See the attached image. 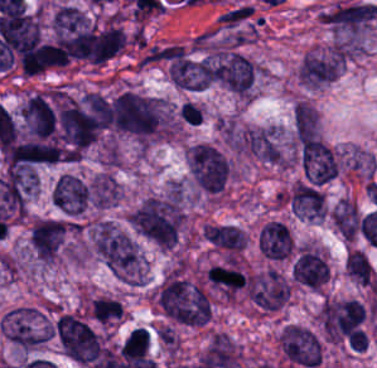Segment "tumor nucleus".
Here are the masks:
<instances>
[{"label": "tumor nucleus", "instance_id": "tumor-nucleus-17", "mask_svg": "<svg viewBox=\"0 0 377 368\" xmlns=\"http://www.w3.org/2000/svg\"><path fill=\"white\" fill-rule=\"evenodd\" d=\"M361 221L355 202L342 198L334 209L333 222L343 237L354 240Z\"/></svg>", "mask_w": 377, "mask_h": 368}, {"label": "tumor nucleus", "instance_id": "tumor-nucleus-2", "mask_svg": "<svg viewBox=\"0 0 377 368\" xmlns=\"http://www.w3.org/2000/svg\"><path fill=\"white\" fill-rule=\"evenodd\" d=\"M376 16L377 6L364 0L342 1L319 15L333 48L348 54L363 50Z\"/></svg>", "mask_w": 377, "mask_h": 368}, {"label": "tumor nucleus", "instance_id": "tumor-nucleus-15", "mask_svg": "<svg viewBox=\"0 0 377 368\" xmlns=\"http://www.w3.org/2000/svg\"><path fill=\"white\" fill-rule=\"evenodd\" d=\"M289 204L296 215L310 221L326 214L324 192L298 181L293 185Z\"/></svg>", "mask_w": 377, "mask_h": 368}, {"label": "tumor nucleus", "instance_id": "tumor-nucleus-16", "mask_svg": "<svg viewBox=\"0 0 377 368\" xmlns=\"http://www.w3.org/2000/svg\"><path fill=\"white\" fill-rule=\"evenodd\" d=\"M120 194V187L114 176L108 172H100L89 183V206L108 207Z\"/></svg>", "mask_w": 377, "mask_h": 368}, {"label": "tumor nucleus", "instance_id": "tumor-nucleus-9", "mask_svg": "<svg viewBox=\"0 0 377 368\" xmlns=\"http://www.w3.org/2000/svg\"><path fill=\"white\" fill-rule=\"evenodd\" d=\"M67 224L53 217H40L31 225L30 246L41 263L59 257L66 236Z\"/></svg>", "mask_w": 377, "mask_h": 368}, {"label": "tumor nucleus", "instance_id": "tumor-nucleus-18", "mask_svg": "<svg viewBox=\"0 0 377 368\" xmlns=\"http://www.w3.org/2000/svg\"><path fill=\"white\" fill-rule=\"evenodd\" d=\"M90 314L98 322H106L123 314L119 301L99 297L90 303Z\"/></svg>", "mask_w": 377, "mask_h": 368}, {"label": "tumor nucleus", "instance_id": "tumor-nucleus-8", "mask_svg": "<svg viewBox=\"0 0 377 368\" xmlns=\"http://www.w3.org/2000/svg\"><path fill=\"white\" fill-rule=\"evenodd\" d=\"M256 74L257 65L245 54L237 51L213 54L210 79L238 95L252 91Z\"/></svg>", "mask_w": 377, "mask_h": 368}, {"label": "tumor nucleus", "instance_id": "tumor-nucleus-6", "mask_svg": "<svg viewBox=\"0 0 377 368\" xmlns=\"http://www.w3.org/2000/svg\"><path fill=\"white\" fill-rule=\"evenodd\" d=\"M64 352L80 361L94 362L103 352V345L94 328L76 313H63L54 325Z\"/></svg>", "mask_w": 377, "mask_h": 368}, {"label": "tumor nucleus", "instance_id": "tumor-nucleus-13", "mask_svg": "<svg viewBox=\"0 0 377 368\" xmlns=\"http://www.w3.org/2000/svg\"><path fill=\"white\" fill-rule=\"evenodd\" d=\"M292 245L290 229L279 220H272L258 234V250L273 260H283L288 257Z\"/></svg>", "mask_w": 377, "mask_h": 368}, {"label": "tumor nucleus", "instance_id": "tumor-nucleus-10", "mask_svg": "<svg viewBox=\"0 0 377 368\" xmlns=\"http://www.w3.org/2000/svg\"><path fill=\"white\" fill-rule=\"evenodd\" d=\"M343 64V53L334 49H314L302 57L299 78L307 86H321L337 75Z\"/></svg>", "mask_w": 377, "mask_h": 368}, {"label": "tumor nucleus", "instance_id": "tumor-nucleus-5", "mask_svg": "<svg viewBox=\"0 0 377 368\" xmlns=\"http://www.w3.org/2000/svg\"><path fill=\"white\" fill-rule=\"evenodd\" d=\"M188 165L191 180L205 193H219L231 174L228 155L210 142H196L189 149Z\"/></svg>", "mask_w": 377, "mask_h": 368}, {"label": "tumor nucleus", "instance_id": "tumor-nucleus-11", "mask_svg": "<svg viewBox=\"0 0 377 368\" xmlns=\"http://www.w3.org/2000/svg\"><path fill=\"white\" fill-rule=\"evenodd\" d=\"M89 183L76 174L63 173L51 189L52 203L64 215L77 216L88 207Z\"/></svg>", "mask_w": 377, "mask_h": 368}, {"label": "tumor nucleus", "instance_id": "tumor-nucleus-4", "mask_svg": "<svg viewBox=\"0 0 377 368\" xmlns=\"http://www.w3.org/2000/svg\"><path fill=\"white\" fill-rule=\"evenodd\" d=\"M164 101L161 95L123 90L113 97L108 113L113 126L149 132L160 123Z\"/></svg>", "mask_w": 377, "mask_h": 368}, {"label": "tumor nucleus", "instance_id": "tumor-nucleus-7", "mask_svg": "<svg viewBox=\"0 0 377 368\" xmlns=\"http://www.w3.org/2000/svg\"><path fill=\"white\" fill-rule=\"evenodd\" d=\"M3 336L23 350H33L50 337V321L35 307H15L1 322Z\"/></svg>", "mask_w": 377, "mask_h": 368}, {"label": "tumor nucleus", "instance_id": "tumor-nucleus-1", "mask_svg": "<svg viewBox=\"0 0 377 368\" xmlns=\"http://www.w3.org/2000/svg\"><path fill=\"white\" fill-rule=\"evenodd\" d=\"M90 245L98 259L118 278L128 283H143L144 256L132 236L104 220L89 226Z\"/></svg>", "mask_w": 377, "mask_h": 368}, {"label": "tumor nucleus", "instance_id": "tumor-nucleus-3", "mask_svg": "<svg viewBox=\"0 0 377 368\" xmlns=\"http://www.w3.org/2000/svg\"><path fill=\"white\" fill-rule=\"evenodd\" d=\"M159 307L172 319L184 324H204L209 319L205 294L199 285L170 274L159 286Z\"/></svg>", "mask_w": 377, "mask_h": 368}, {"label": "tumor nucleus", "instance_id": "tumor-nucleus-12", "mask_svg": "<svg viewBox=\"0 0 377 368\" xmlns=\"http://www.w3.org/2000/svg\"><path fill=\"white\" fill-rule=\"evenodd\" d=\"M205 279L217 293L235 298L248 281V274L238 260L225 259L211 265Z\"/></svg>", "mask_w": 377, "mask_h": 368}, {"label": "tumor nucleus", "instance_id": "tumor-nucleus-14", "mask_svg": "<svg viewBox=\"0 0 377 368\" xmlns=\"http://www.w3.org/2000/svg\"><path fill=\"white\" fill-rule=\"evenodd\" d=\"M329 278L327 262L314 249L304 245L295 265L294 280L313 289H320Z\"/></svg>", "mask_w": 377, "mask_h": 368}]
</instances>
